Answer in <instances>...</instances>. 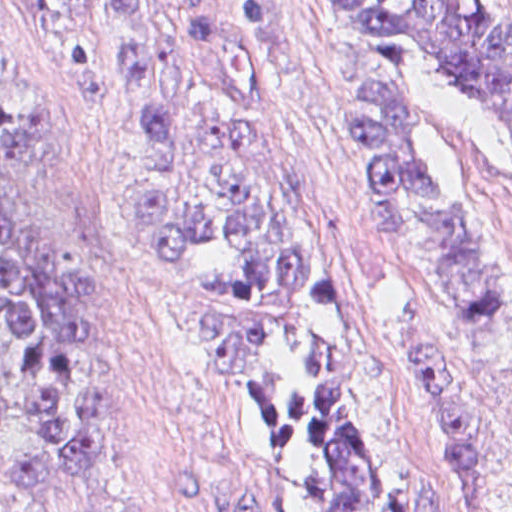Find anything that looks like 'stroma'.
Returning <instances> with one entry per match:
<instances>
[{"instance_id":"obj_1","label":"stroma","mask_w":512,"mask_h":512,"mask_svg":"<svg viewBox=\"0 0 512 512\" xmlns=\"http://www.w3.org/2000/svg\"><path fill=\"white\" fill-rule=\"evenodd\" d=\"M261 1L294 89L298 177L332 293L382 386L380 511L512 512L509 113L494 91L439 58L406 91L410 156L495 278V322H468L375 237L350 82L318 0ZM471 2L512 54V0ZM0 24L51 92L49 129L23 178L100 249L125 337V399L98 494L89 506H35L0 491V512H194L177 485L187 471L254 491L263 512H292L245 371L136 201L126 86L37 36L25 0H0Z\"/></svg>"}]
</instances>
